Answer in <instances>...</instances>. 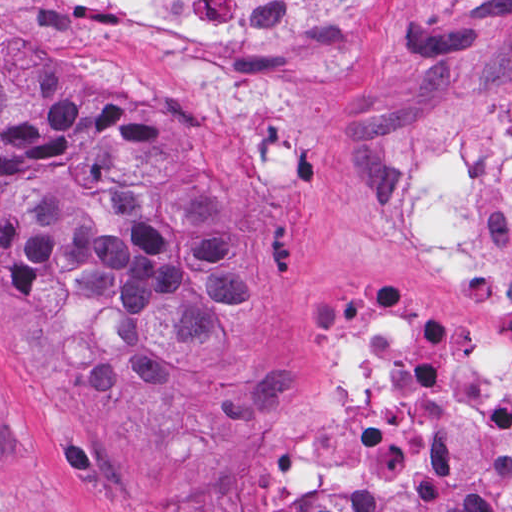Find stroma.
Listing matches in <instances>:
<instances>
[{
    "instance_id": "stroma-1",
    "label": "stroma",
    "mask_w": 512,
    "mask_h": 512,
    "mask_svg": "<svg viewBox=\"0 0 512 512\" xmlns=\"http://www.w3.org/2000/svg\"><path fill=\"white\" fill-rule=\"evenodd\" d=\"M27 53L65 60L87 92L126 101L217 170L242 198L266 292L234 336L233 373L184 410L48 400L0 335V512H254L316 491L512 512V488L488 478L307 490L250 477L261 447L320 439L315 350L347 303L406 305L443 347L512 361V321L484 320L398 247L412 158L433 139L491 142L512 111V0H382L375 44L247 129L207 120L199 89L108 0H0V57Z\"/></svg>"
}]
</instances>
